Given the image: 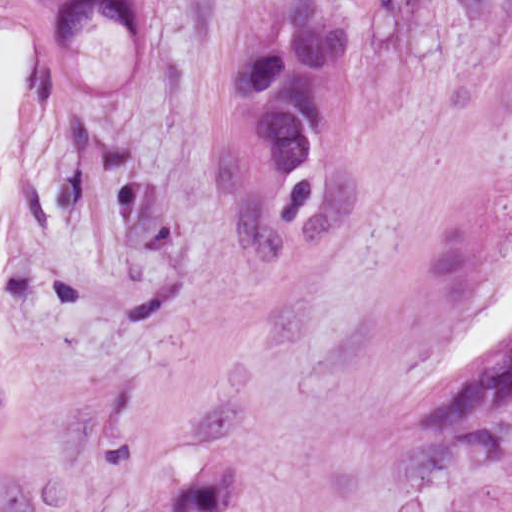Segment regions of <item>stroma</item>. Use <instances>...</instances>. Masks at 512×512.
<instances>
[{
	"mask_svg": "<svg viewBox=\"0 0 512 512\" xmlns=\"http://www.w3.org/2000/svg\"><path fill=\"white\" fill-rule=\"evenodd\" d=\"M69 1L12 0L40 50L0 201V512H512V435L466 461L398 414L512 271V0H316L350 69L297 232L233 99L291 0H147L151 36L57 49Z\"/></svg>",
	"mask_w": 512,
	"mask_h": 512,
	"instance_id": "stroma-1",
	"label": "stroma"
}]
</instances>
